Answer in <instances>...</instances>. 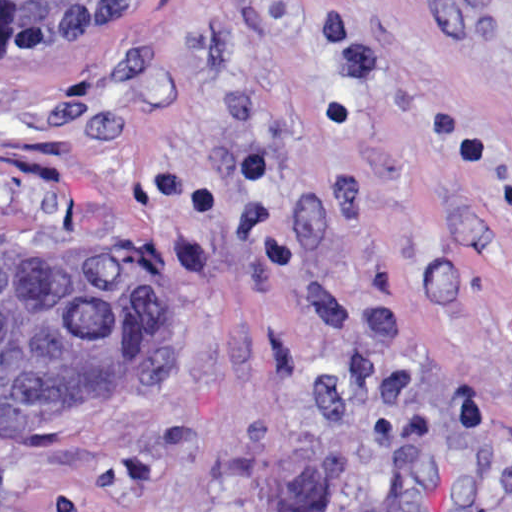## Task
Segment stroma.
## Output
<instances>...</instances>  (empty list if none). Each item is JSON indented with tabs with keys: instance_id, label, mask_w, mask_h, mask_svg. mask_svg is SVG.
Segmentation results:
<instances>
[{
	"instance_id": "1",
	"label": "stroma",
	"mask_w": 512,
	"mask_h": 512,
	"mask_svg": "<svg viewBox=\"0 0 512 512\" xmlns=\"http://www.w3.org/2000/svg\"><path fill=\"white\" fill-rule=\"evenodd\" d=\"M189 248L179 382L0 432V512H512V0H135L0 47V247Z\"/></svg>"
}]
</instances>
